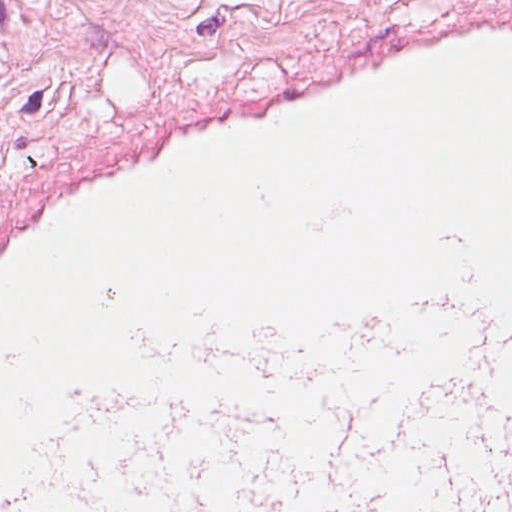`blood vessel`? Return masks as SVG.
I'll list each match as a JSON object with an SVG mask.
<instances>
[{"instance_id":"8fb6f2fc","label":"blood vessel","mask_w":512,"mask_h":512,"mask_svg":"<svg viewBox=\"0 0 512 512\" xmlns=\"http://www.w3.org/2000/svg\"><path fill=\"white\" fill-rule=\"evenodd\" d=\"M440 240L512 303V5L298 54L239 335L439 291Z\"/></svg>"}]
</instances>
